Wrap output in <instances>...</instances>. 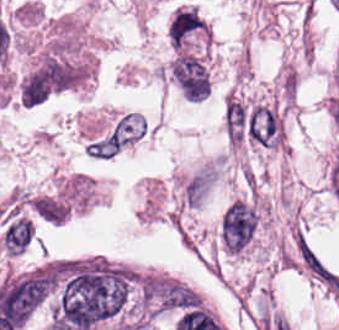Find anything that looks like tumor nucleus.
<instances>
[{
	"instance_id": "2f306a5c",
	"label": "tumor nucleus",
	"mask_w": 339,
	"mask_h": 330,
	"mask_svg": "<svg viewBox=\"0 0 339 330\" xmlns=\"http://www.w3.org/2000/svg\"><path fill=\"white\" fill-rule=\"evenodd\" d=\"M170 74L179 91L191 103H199L209 97V73L203 60L194 53L178 50Z\"/></svg>"
},
{
	"instance_id": "8643909e",
	"label": "tumor nucleus",
	"mask_w": 339,
	"mask_h": 330,
	"mask_svg": "<svg viewBox=\"0 0 339 330\" xmlns=\"http://www.w3.org/2000/svg\"><path fill=\"white\" fill-rule=\"evenodd\" d=\"M255 213L241 203L230 206L222 223L221 233L229 252L239 253L256 228Z\"/></svg>"
}]
</instances>
